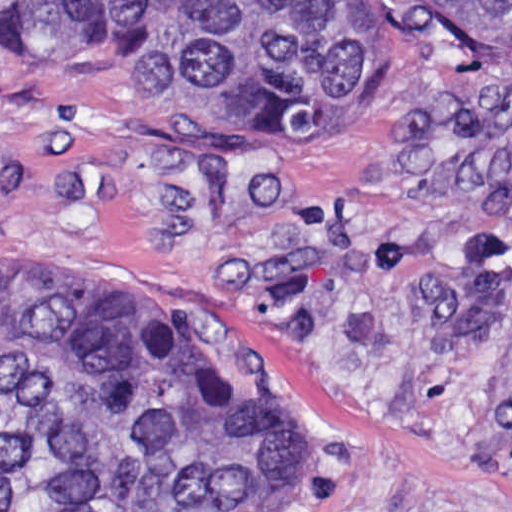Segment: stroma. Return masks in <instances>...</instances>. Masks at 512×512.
<instances>
[{
  "label": "stroma",
  "mask_w": 512,
  "mask_h": 512,
  "mask_svg": "<svg viewBox=\"0 0 512 512\" xmlns=\"http://www.w3.org/2000/svg\"><path fill=\"white\" fill-rule=\"evenodd\" d=\"M213 311L242 401L324 431L318 512H512V63L416 51L362 128L147 117L0 70V244Z\"/></svg>",
  "instance_id": "stroma-1"
}]
</instances>
